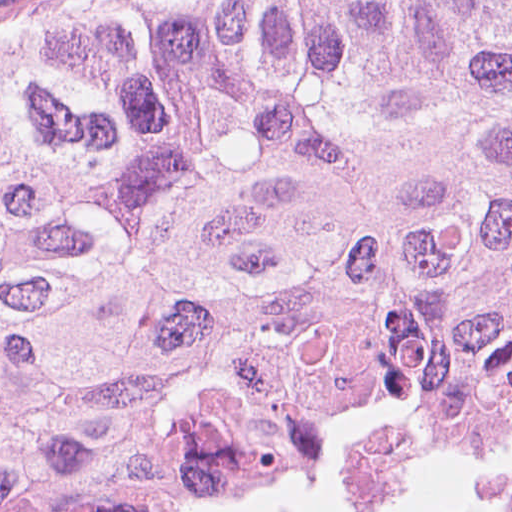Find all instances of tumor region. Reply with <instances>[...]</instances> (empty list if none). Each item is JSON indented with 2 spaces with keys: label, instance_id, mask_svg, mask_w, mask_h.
<instances>
[{
  "label": "tumor region",
  "instance_id": "1",
  "mask_svg": "<svg viewBox=\"0 0 512 512\" xmlns=\"http://www.w3.org/2000/svg\"><path fill=\"white\" fill-rule=\"evenodd\" d=\"M512 441V0H166L0 50V512H201Z\"/></svg>",
  "mask_w": 512,
  "mask_h": 512
}]
</instances>
